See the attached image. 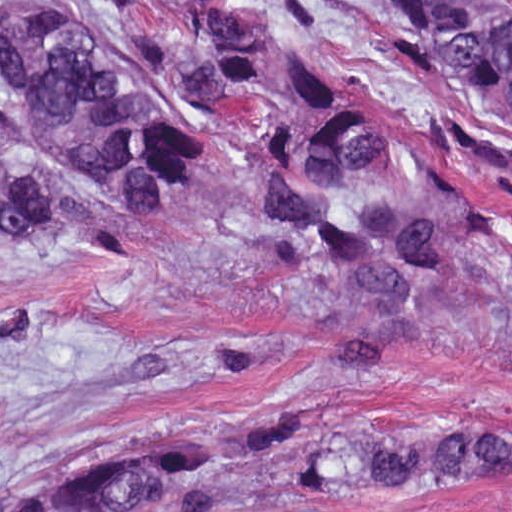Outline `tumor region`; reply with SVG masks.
Returning <instances> with one entry per match:
<instances>
[{
	"label": "tumor region",
	"mask_w": 512,
	"mask_h": 512,
	"mask_svg": "<svg viewBox=\"0 0 512 512\" xmlns=\"http://www.w3.org/2000/svg\"><path fill=\"white\" fill-rule=\"evenodd\" d=\"M108 1H1V223L99 250L80 198L12 163L24 114L55 165L158 224L203 153V127L113 83L94 43ZM173 20L190 98L244 95L264 63L273 1H148ZM426 62L512 111V1H370ZM267 304L337 364L512 318V237L450 157L357 106L322 73L282 69L244 166ZM221 432L131 447L12 484L55 453L1 431V512H257L317 493L462 487L512 472L496 420L377 435L327 403L249 407Z\"/></svg>",
	"instance_id": "1"
}]
</instances>
